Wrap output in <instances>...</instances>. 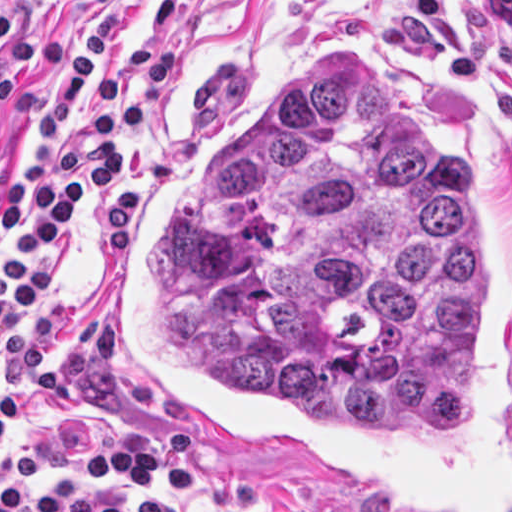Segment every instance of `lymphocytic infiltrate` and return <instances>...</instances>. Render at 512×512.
I'll return each instance as SVG.
<instances>
[{"instance_id": "lymphocytic-infiltrate-1", "label": "lymphocytic infiltrate", "mask_w": 512, "mask_h": 512, "mask_svg": "<svg viewBox=\"0 0 512 512\" xmlns=\"http://www.w3.org/2000/svg\"><path fill=\"white\" fill-rule=\"evenodd\" d=\"M15 25L16 10L0 11L1 106L14 99L9 77L38 59L29 30L17 51L2 48ZM116 30L117 2L99 0L46 57L26 163L1 191L8 252L0 263V339L48 289L78 216L122 182L127 155L182 72L178 44H153L132 75H119L110 66ZM377 39L430 57L463 98L500 117L512 140V0H412ZM19 407L20 386L6 375L0 341V445ZM43 470L81 474L94 485H38L31 476ZM198 477L197 440L173 430L128 433L94 447L17 456L0 473V512H183L156 496L177 495Z\"/></svg>"}]
</instances>
